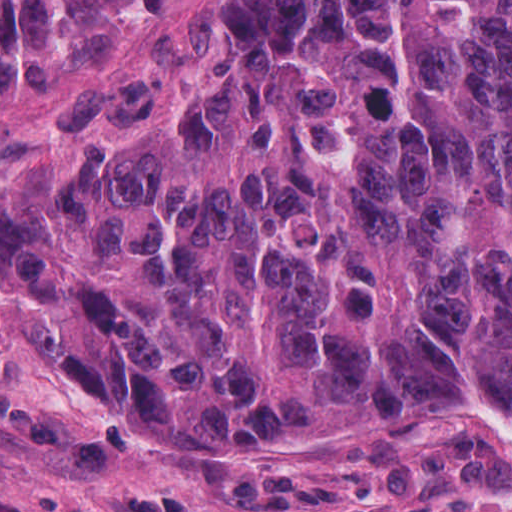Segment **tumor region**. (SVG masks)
Here are the masks:
<instances>
[{
	"mask_svg": "<svg viewBox=\"0 0 512 512\" xmlns=\"http://www.w3.org/2000/svg\"><path fill=\"white\" fill-rule=\"evenodd\" d=\"M0 274L116 426L512 415V0H0Z\"/></svg>",
	"mask_w": 512,
	"mask_h": 512,
	"instance_id": "e687c5a6",
	"label": "tumor region"
}]
</instances>
